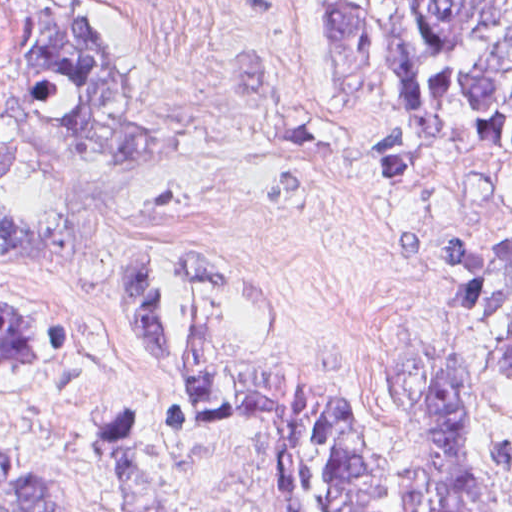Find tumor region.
Segmentation results:
<instances>
[{"label":"tumor region","instance_id":"obj_1","mask_svg":"<svg viewBox=\"0 0 512 512\" xmlns=\"http://www.w3.org/2000/svg\"><path fill=\"white\" fill-rule=\"evenodd\" d=\"M112 0H0V252L40 258L129 287L137 320L184 390L162 427L230 415L264 422L287 512H510L512 439L467 409L472 360L414 337L377 360L394 414L384 424L354 394L273 357V301L218 248L186 255L177 327L158 252H139L135 199L158 136L135 75L113 46ZM321 51L346 90L387 55L404 131L356 140L371 178H436L475 147L512 163V0H319ZM149 124V136L144 118ZM406 262L447 260L461 321L512 313V232L482 225L431 246L406 223ZM64 354L57 316L0 292V386L24 389ZM484 369L512 375V334ZM41 374V380L38 378ZM93 444L125 512H185L183 483L155 456L139 406L103 412ZM0 512H53L38 467L0 443Z\"/></svg>","mask_w":512,"mask_h":512}]
</instances>
